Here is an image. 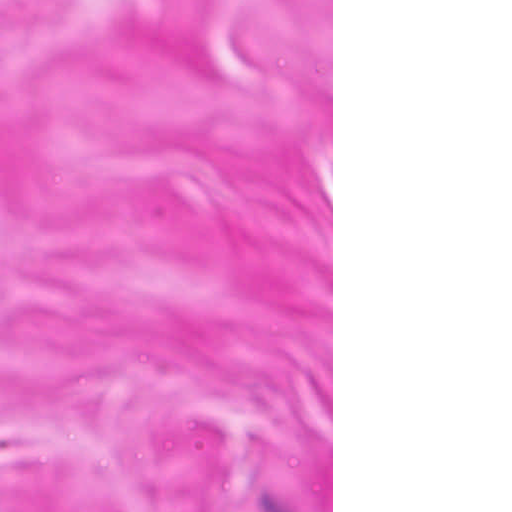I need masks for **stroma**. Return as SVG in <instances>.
Masks as SVG:
<instances>
[{
	"label": "stroma",
	"instance_id": "1",
	"mask_svg": "<svg viewBox=\"0 0 512 512\" xmlns=\"http://www.w3.org/2000/svg\"><path fill=\"white\" fill-rule=\"evenodd\" d=\"M0 512H333V0H0Z\"/></svg>",
	"mask_w": 512,
	"mask_h": 512
}]
</instances>
